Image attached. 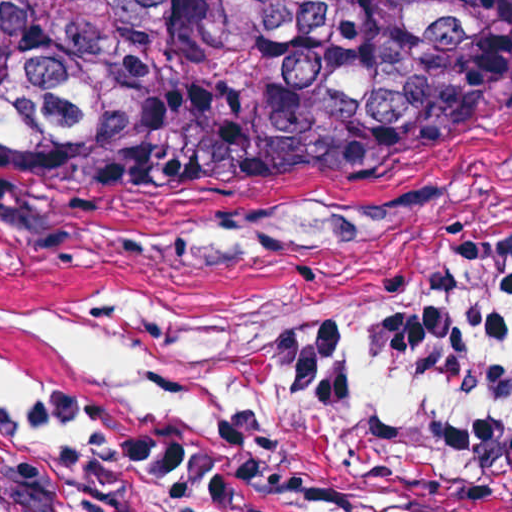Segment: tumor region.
I'll list each match as a JSON object with an SVG mask.
<instances>
[{
    "label": "tumor region",
    "mask_w": 512,
    "mask_h": 512,
    "mask_svg": "<svg viewBox=\"0 0 512 512\" xmlns=\"http://www.w3.org/2000/svg\"><path fill=\"white\" fill-rule=\"evenodd\" d=\"M512 124V0H0V196L244 241Z\"/></svg>",
    "instance_id": "obj_1"
}]
</instances>
